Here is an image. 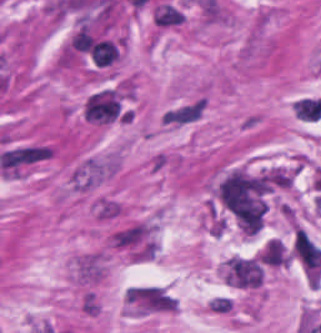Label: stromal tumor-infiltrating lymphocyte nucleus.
Returning <instances> with one entry per match:
<instances>
[{"instance_id": "bc302bb0", "label": "stromal tumor-infiltrating lymphocyte nucleus", "mask_w": 321, "mask_h": 333, "mask_svg": "<svg viewBox=\"0 0 321 333\" xmlns=\"http://www.w3.org/2000/svg\"><path fill=\"white\" fill-rule=\"evenodd\" d=\"M90 57L95 64L106 65L119 59L116 45L110 38H96L89 46Z\"/></svg>"}]
</instances>
